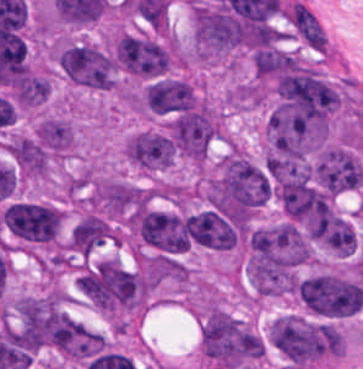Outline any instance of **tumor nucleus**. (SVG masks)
Returning a JSON list of instances; mask_svg holds the SVG:
<instances>
[{
    "mask_svg": "<svg viewBox=\"0 0 363 369\" xmlns=\"http://www.w3.org/2000/svg\"><path fill=\"white\" fill-rule=\"evenodd\" d=\"M112 54L116 68L138 77H163L171 62L165 42L127 31L113 41Z\"/></svg>",
    "mask_w": 363,
    "mask_h": 369,
    "instance_id": "tumor-nucleus-5",
    "label": "tumor nucleus"
},
{
    "mask_svg": "<svg viewBox=\"0 0 363 369\" xmlns=\"http://www.w3.org/2000/svg\"><path fill=\"white\" fill-rule=\"evenodd\" d=\"M295 292L310 314L343 319L355 315L363 286L351 277L320 272L295 282Z\"/></svg>",
    "mask_w": 363,
    "mask_h": 369,
    "instance_id": "tumor-nucleus-2",
    "label": "tumor nucleus"
},
{
    "mask_svg": "<svg viewBox=\"0 0 363 369\" xmlns=\"http://www.w3.org/2000/svg\"><path fill=\"white\" fill-rule=\"evenodd\" d=\"M69 242L83 258H90L107 242L105 223L86 212L72 229Z\"/></svg>",
    "mask_w": 363,
    "mask_h": 369,
    "instance_id": "tumor-nucleus-8",
    "label": "tumor nucleus"
},
{
    "mask_svg": "<svg viewBox=\"0 0 363 369\" xmlns=\"http://www.w3.org/2000/svg\"><path fill=\"white\" fill-rule=\"evenodd\" d=\"M282 18L296 38L312 50L326 51V31L306 4L286 3Z\"/></svg>",
    "mask_w": 363,
    "mask_h": 369,
    "instance_id": "tumor-nucleus-6",
    "label": "tumor nucleus"
},
{
    "mask_svg": "<svg viewBox=\"0 0 363 369\" xmlns=\"http://www.w3.org/2000/svg\"><path fill=\"white\" fill-rule=\"evenodd\" d=\"M57 64L69 80L83 88L107 91L115 87L112 55L95 44L62 38L57 44Z\"/></svg>",
    "mask_w": 363,
    "mask_h": 369,
    "instance_id": "tumor-nucleus-3",
    "label": "tumor nucleus"
},
{
    "mask_svg": "<svg viewBox=\"0 0 363 369\" xmlns=\"http://www.w3.org/2000/svg\"><path fill=\"white\" fill-rule=\"evenodd\" d=\"M0 219L5 230L24 245L46 246L56 239L63 213L52 203L13 200Z\"/></svg>",
    "mask_w": 363,
    "mask_h": 369,
    "instance_id": "tumor-nucleus-4",
    "label": "tumor nucleus"
},
{
    "mask_svg": "<svg viewBox=\"0 0 363 369\" xmlns=\"http://www.w3.org/2000/svg\"><path fill=\"white\" fill-rule=\"evenodd\" d=\"M35 138L49 155L63 156L74 145L73 125L59 117L48 116L37 122Z\"/></svg>",
    "mask_w": 363,
    "mask_h": 369,
    "instance_id": "tumor-nucleus-7",
    "label": "tumor nucleus"
},
{
    "mask_svg": "<svg viewBox=\"0 0 363 369\" xmlns=\"http://www.w3.org/2000/svg\"><path fill=\"white\" fill-rule=\"evenodd\" d=\"M269 344L295 369H308L327 357V322L283 314L268 328Z\"/></svg>",
    "mask_w": 363,
    "mask_h": 369,
    "instance_id": "tumor-nucleus-1",
    "label": "tumor nucleus"
}]
</instances>
